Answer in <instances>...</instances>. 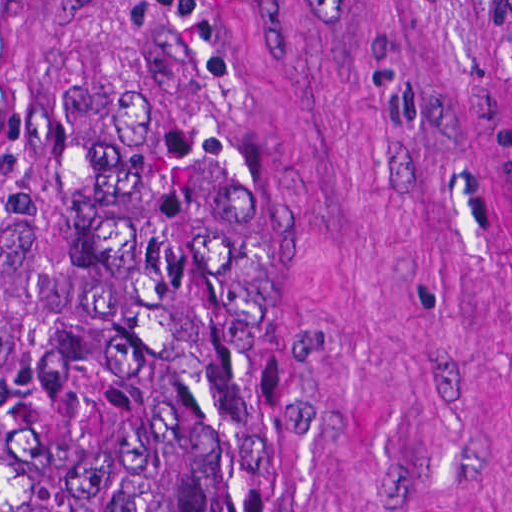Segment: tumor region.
<instances>
[{
    "mask_svg": "<svg viewBox=\"0 0 512 512\" xmlns=\"http://www.w3.org/2000/svg\"><path fill=\"white\" fill-rule=\"evenodd\" d=\"M503 57L512 0H480ZM248 166L181 0H138L65 249L0 386V512H214L242 452Z\"/></svg>",
    "mask_w": 512,
    "mask_h": 512,
    "instance_id": "1",
    "label": "tumor region"
}]
</instances>
